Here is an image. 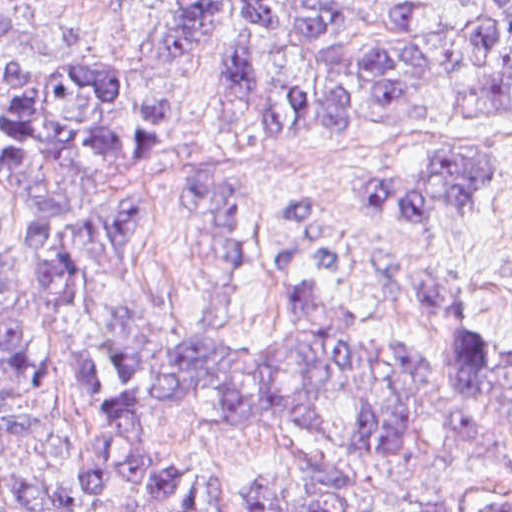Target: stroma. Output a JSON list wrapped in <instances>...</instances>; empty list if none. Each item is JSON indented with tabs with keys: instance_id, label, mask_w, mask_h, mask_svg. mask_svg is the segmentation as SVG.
Listing matches in <instances>:
<instances>
[{
	"instance_id": "1",
	"label": "stroma",
	"mask_w": 512,
	"mask_h": 512,
	"mask_svg": "<svg viewBox=\"0 0 512 512\" xmlns=\"http://www.w3.org/2000/svg\"><path fill=\"white\" fill-rule=\"evenodd\" d=\"M47 19L11 33L20 66L75 65L96 73L140 155L94 166L84 207L137 211L110 291L73 288L57 317L23 307L33 354L28 389L6 405L49 434H0L13 459L51 489L58 512H125L80 496L81 441L102 427L67 390L64 359H88L109 396L117 378L107 347L117 318L157 313L196 333L209 372H305L329 362H257L231 356L209 333L263 335L281 327L278 297L330 286L348 328L376 348L440 346L512 353V109L473 114L438 91L411 117L338 118L318 134H246L214 123V98L192 52L154 62L149 39L161 0H36ZM165 95L172 126L151 153L141 102ZM495 157L480 198L432 223L393 213L360 192L369 176H403L440 155ZM18 202L0 182V237L16 245ZM419 276H456L472 307L435 338L391 293ZM2 372L0 369V382ZM368 402L335 415L338 436L290 422L232 423L205 402L157 415L166 451L206 465L219 512H259L248 490H304L331 512H512V415H492L465 441L449 425L460 397L433 395L403 418L407 442L362 452Z\"/></svg>"
}]
</instances>
